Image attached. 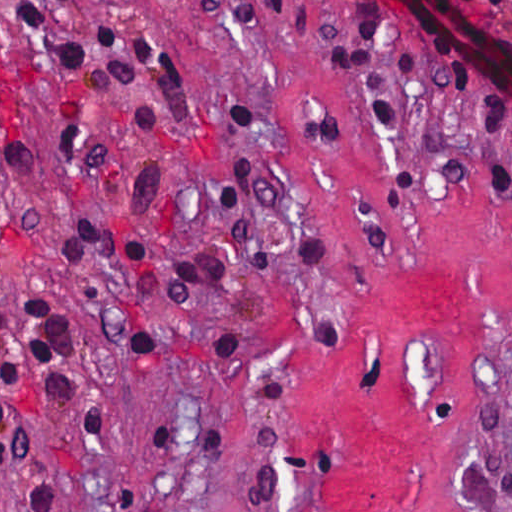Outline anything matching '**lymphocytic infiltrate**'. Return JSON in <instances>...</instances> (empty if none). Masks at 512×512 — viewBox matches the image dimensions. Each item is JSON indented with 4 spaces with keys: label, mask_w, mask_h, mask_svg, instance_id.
<instances>
[{
    "label": "lymphocytic infiltrate",
    "mask_w": 512,
    "mask_h": 512,
    "mask_svg": "<svg viewBox=\"0 0 512 512\" xmlns=\"http://www.w3.org/2000/svg\"><path fill=\"white\" fill-rule=\"evenodd\" d=\"M512 16V0H473ZM108 0H22L18 26L28 44L70 79L96 90L123 119L150 139L167 138L184 109V67L173 48L144 25L104 14ZM287 34L303 49L344 69L365 116L377 127L401 130L397 120V68L369 41L346 38L332 16L311 0H267ZM442 67L462 98L473 125V160L485 194L512 204V165L505 138L512 129V101L456 54H440ZM253 165L239 160L224 167L214 192L217 246L201 250L185 265L157 259L150 228L164 198V174L143 162L128 179L122 228L74 223L56 240L70 260L96 259L137 277L133 297L141 306L157 276L172 304H189L199 290L216 287L231 272H292L332 276L339 252L311 238L296 247L272 248L249 222ZM174 342L211 358H236L235 335L192 337L151 329V351ZM512 493V472L502 478Z\"/></svg>",
    "instance_id": "1"
}]
</instances>
